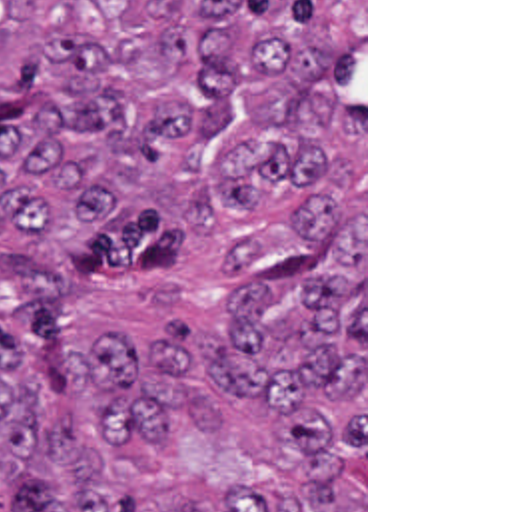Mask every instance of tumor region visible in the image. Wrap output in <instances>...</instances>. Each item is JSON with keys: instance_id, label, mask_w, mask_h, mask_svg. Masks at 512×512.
Here are the masks:
<instances>
[{"instance_id": "obj_1", "label": "tumor region", "mask_w": 512, "mask_h": 512, "mask_svg": "<svg viewBox=\"0 0 512 512\" xmlns=\"http://www.w3.org/2000/svg\"><path fill=\"white\" fill-rule=\"evenodd\" d=\"M364 0H0V512H364Z\"/></svg>"}]
</instances>
